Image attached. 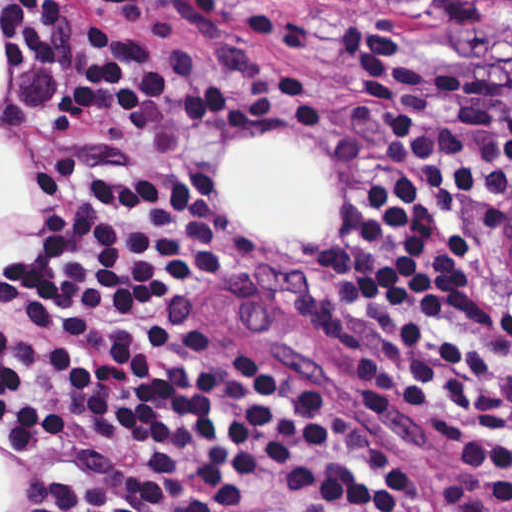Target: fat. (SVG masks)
<instances>
[{
  "instance_id": "1",
  "label": "fat",
  "mask_w": 512,
  "mask_h": 512,
  "mask_svg": "<svg viewBox=\"0 0 512 512\" xmlns=\"http://www.w3.org/2000/svg\"><path fill=\"white\" fill-rule=\"evenodd\" d=\"M226 222L272 244H312L335 213V185L306 148L254 136L228 153L217 179Z\"/></svg>"
}]
</instances>
